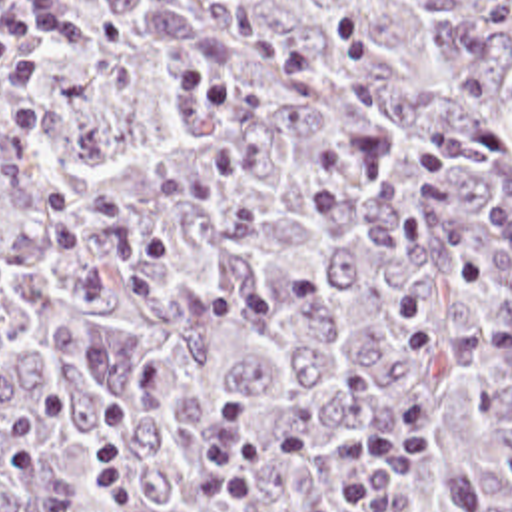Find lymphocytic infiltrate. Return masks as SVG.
Here are the masks:
<instances>
[{
    "label": "lymphocytic infiltrate",
    "mask_w": 512,
    "mask_h": 512,
    "mask_svg": "<svg viewBox=\"0 0 512 512\" xmlns=\"http://www.w3.org/2000/svg\"><path fill=\"white\" fill-rule=\"evenodd\" d=\"M67 25V0H0V75L11 83L37 81L49 49ZM430 401L408 393L378 423L350 437H262L248 441L244 409L229 403L215 445L201 504L242 510L252 504L264 465L322 461L352 473L350 491L314 512H406L414 469L428 439ZM133 413L113 405L97 429V489L113 508H131L133 479L125 439Z\"/></svg>",
    "instance_id": "f902f5d3"
}]
</instances>
